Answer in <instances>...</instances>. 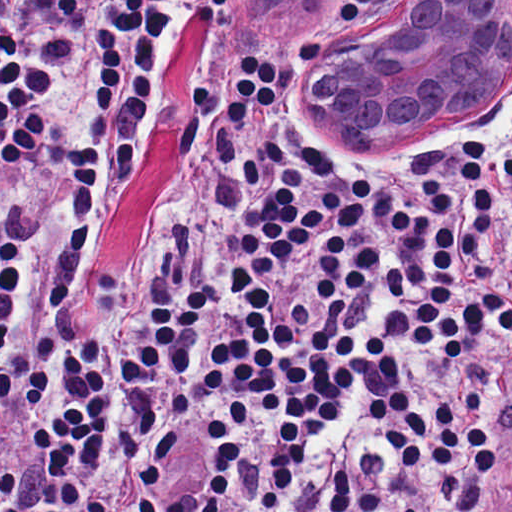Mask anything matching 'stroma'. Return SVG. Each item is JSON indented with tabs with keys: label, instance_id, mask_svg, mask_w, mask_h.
Here are the masks:
<instances>
[{
	"label": "stroma",
	"instance_id": "obj_1",
	"mask_svg": "<svg viewBox=\"0 0 512 512\" xmlns=\"http://www.w3.org/2000/svg\"><path fill=\"white\" fill-rule=\"evenodd\" d=\"M392 0H313L306 12L292 19L255 13L246 0H230L226 12H192L172 62L169 92L184 82L199 60L228 41H259L288 62L290 77L297 80L312 111H326L336 97L332 70L345 46ZM217 61L223 60L217 51ZM476 129H483L509 148V216L512 214V101ZM341 138V137H340ZM343 139L356 152L370 151L384 157H403L420 146H367L369 132L356 123ZM149 204V139L146 168L127 199L118 234L104 241L89 278L66 307L57 341V406L37 432L27 455L0 468V475L34 454L52 420L62 391V357L74 327L118 285L139 252L146 233Z\"/></svg>",
	"mask_w": 512,
	"mask_h": 512
}]
</instances>
